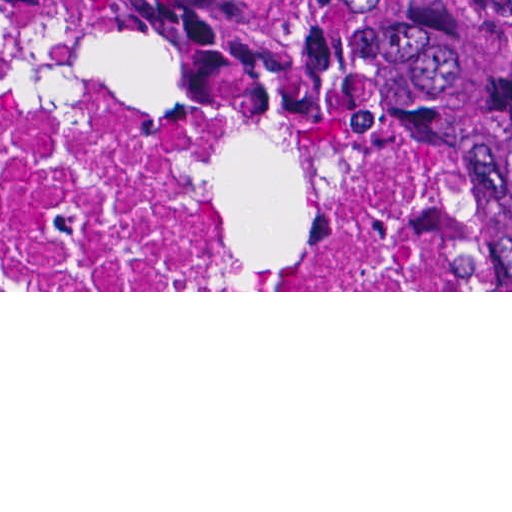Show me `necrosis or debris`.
I'll return each mask as SVG.
<instances>
[{
    "mask_svg": "<svg viewBox=\"0 0 512 512\" xmlns=\"http://www.w3.org/2000/svg\"><path fill=\"white\" fill-rule=\"evenodd\" d=\"M457 186L383 125L0 19V290H475Z\"/></svg>",
    "mask_w": 512,
    "mask_h": 512,
    "instance_id": "1",
    "label": "necrosis or debris"
}]
</instances>
